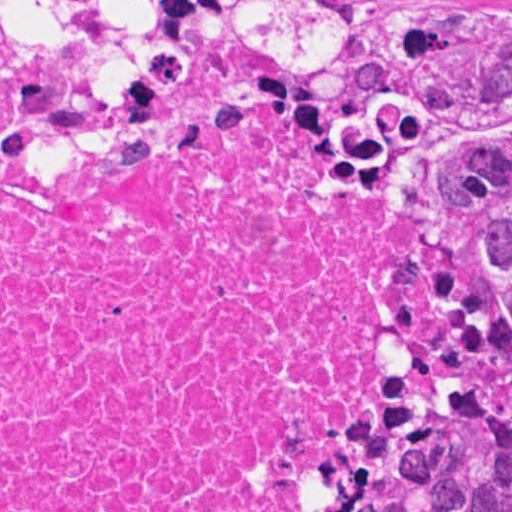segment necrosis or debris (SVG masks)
<instances>
[{
    "label": "necrosis or debris",
    "mask_w": 512,
    "mask_h": 512,
    "mask_svg": "<svg viewBox=\"0 0 512 512\" xmlns=\"http://www.w3.org/2000/svg\"><path fill=\"white\" fill-rule=\"evenodd\" d=\"M467 303L440 149L215 80L102 139L0 19V512H373Z\"/></svg>",
    "instance_id": "necrosis-or-debris-1"
}]
</instances>
